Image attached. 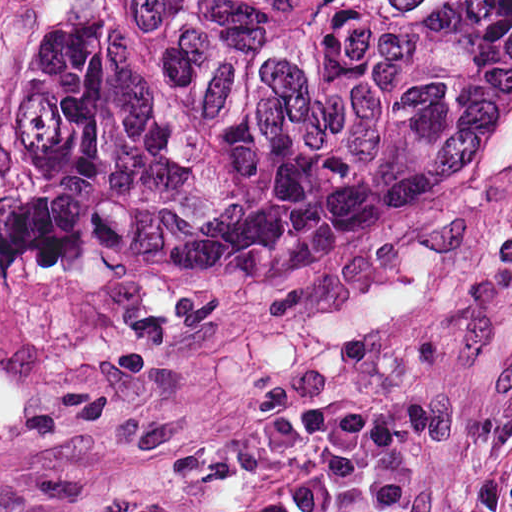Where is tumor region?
Wrapping results in <instances>:
<instances>
[{
	"label": "tumor region",
	"mask_w": 512,
	"mask_h": 512,
	"mask_svg": "<svg viewBox=\"0 0 512 512\" xmlns=\"http://www.w3.org/2000/svg\"><path fill=\"white\" fill-rule=\"evenodd\" d=\"M512 147V0H58L0 125V263L346 261Z\"/></svg>",
	"instance_id": "tumor-region-1"
}]
</instances>
